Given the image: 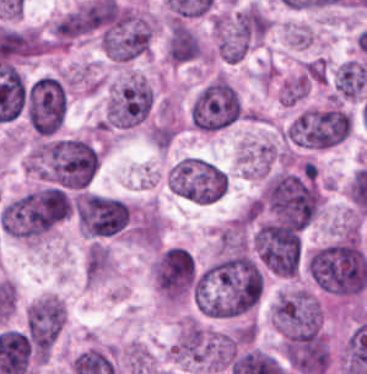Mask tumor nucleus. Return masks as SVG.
<instances>
[{"label": "tumor nucleus", "mask_w": 367, "mask_h": 374, "mask_svg": "<svg viewBox=\"0 0 367 374\" xmlns=\"http://www.w3.org/2000/svg\"><path fill=\"white\" fill-rule=\"evenodd\" d=\"M264 269L250 252L226 248L197 274L192 295L194 305L209 315L244 313L262 294Z\"/></svg>", "instance_id": "1"}, {"label": "tumor nucleus", "mask_w": 367, "mask_h": 374, "mask_svg": "<svg viewBox=\"0 0 367 374\" xmlns=\"http://www.w3.org/2000/svg\"><path fill=\"white\" fill-rule=\"evenodd\" d=\"M99 164V153L86 137L42 136L29 150L26 165L48 183L82 189Z\"/></svg>", "instance_id": "2"}, {"label": "tumor nucleus", "mask_w": 367, "mask_h": 374, "mask_svg": "<svg viewBox=\"0 0 367 374\" xmlns=\"http://www.w3.org/2000/svg\"><path fill=\"white\" fill-rule=\"evenodd\" d=\"M306 270L318 290L338 296L362 292L366 283V253L360 239H334L312 250Z\"/></svg>", "instance_id": "3"}, {"label": "tumor nucleus", "mask_w": 367, "mask_h": 374, "mask_svg": "<svg viewBox=\"0 0 367 374\" xmlns=\"http://www.w3.org/2000/svg\"><path fill=\"white\" fill-rule=\"evenodd\" d=\"M61 217V189L45 185L5 203L0 210V228L11 238L33 242L53 229Z\"/></svg>", "instance_id": "4"}, {"label": "tumor nucleus", "mask_w": 367, "mask_h": 374, "mask_svg": "<svg viewBox=\"0 0 367 374\" xmlns=\"http://www.w3.org/2000/svg\"><path fill=\"white\" fill-rule=\"evenodd\" d=\"M351 114L342 103L306 106L284 125V134L296 146L326 147L349 134Z\"/></svg>", "instance_id": "5"}, {"label": "tumor nucleus", "mask_w": 367, "mask_h": 374, "mask_svg": "<svg viewBox=\"0 0 367 374\" xmlns=\"http://www.w3.org/2000/svg\"><path fill=\"white\" fill-rule=\"evenodd\" d=\"M152 21L146 11L115 4L98 34L103 54L130 60L148 50Z\"/></svg>", "instance_id": "6"}, {"label": "tumor nucleus", "mask_w": 367, "mask_h": 374, "mask_svg": "<svg viewBox=\"0 0 367 374\" xmlns=\"http://www.w3.org/2000/svg\"><path fill=\"white\" fill-rule=\"evenodd\" d=\"M166 180L173 194L200 204L220 199L228 184L220 168L197 156L176 161L166 172Z\"/></svg>", "instance_id": "7"}, {"label": "tumor nucleus", "mask_w": 367, "mask_h": 374, "mask_svg": "<svg viewBox=\"0 0 367 374\" xmlns=\"http://www.w3.org/2000/svg\"><path fill=\"white\" fill-rule=\"evenodd\" d=\"M192 124L215 131L243 114L238 90L223 75H215L201 86L189 106Z\"/></svg>", "instance_id": "8"}, {"label": "tumor nucleus", "mask_w": 367, "mask_h": 374, "mask_svg": "<svg viewBox=\"0 0 367 374\" xmlns=\"http://www.w3.org/2000/svg\"><path fill=\"white\" fill-rule=\"evenodd\" d=\"M152 95L146 77L129 73L111 90L102 112L103 129H127L143 123Z\"/></svg>", "instance_id": "9"}, {"label": "tumor nucleus", "mask_w": 367, "mask_h": 374, "mask_svg": "<svg viewBox=\"0 0 367 374\" xmlns=\"http://www.w3.org/2000/svg\"><path fill=\"white\" fill-rule=\"evenodd\" d=\"M80 229L91 237H112L130 227L134 211L124 200L91 192L75 199Z\"/></svg>", "instance_id": "10"}, {"label": "tumor nucleus", "mask_w": 367, "mask_h": 374, "mask_svg": "<svg viewBox=\"0 0 367 374\" xmlns=\"http://www.w3.org/2000/svg\"><path fill=\"white\" fill-rule=\"evenodd\" d=\"M195 272L193 257L181 244L160 247L152 259V281L160 296L168 301L188 298Z\"/></svg>", "instance_id": "11"}, {"label": "tumor nucleus", "mask_w": 367, "mask_h": 374, "mask_svg": "<svg viewBox=\"0 0 367 374\" xmlns=\"http://www.w3.org/2000/svg\"><path fill=\"white\" fill-rule=\"evenodd\" d=\"M25 111L29 127L36 134H53L66 115V89L52 76L37 77L25 91Z\"/></svg>", "instance_id": "12"}, {"label": "tumor nucleus", "mask_w": 367, "mask_h": 374, "mask_svg": "<svg viewBox=\"0 0 367 374\" xmlns=\"http://www.w3.org/2000/svg\"><path fill=\"white\" fill-rule=\"evenodd\" d=\"M65 320L64 301L43 293L25 310V332L32 353L46 359Z\"/></svg>", "instance_id": "13"}, {"label": "tumor nucleus", "mask_w": 367, "mask_h": 374, "mask_svg": "<svg viewBox=\"0 0 367 374\" xmlns=\"http://www.w3.org/2000/svg\"><path fill=\"white\" fill-rule=\"evenodd\" d=\"M320 316L318 297L306 287L278 292L271 307V320L280 334L314 328L319 324Z\"/></svg>", "instance_id": "14"}, {"label": "tumor nucleus", "mask_w": 367, "mask_h": 374, "mask_svg": "<svg viewBox=\"0 0 367 374\" xmlns=\"http://www.w3.org/2000/svg\"><path fill=\"white\" fill-rule=\"evenodd\" d=\"M201 55V41L186 22L171 20L168 25L166 58L169 64L180 65Z\"/></svg>", "instance_id": "15"}, {"label": "tumor nucleus", "mask_w": 367, "mask_h": 374, "mask_svg": "<svg viewBox=\"0 0 367 374\" xmlns=\"http://www.w3.org/2000/svg\"><path fill=\"white\" fill-rule=\"evenodd\" d=\"M335 97L361 99L367 87V67L362 60L348 59L336 67L332 74Z\"/></svg>", "instance_id": "16"}, {"label": "tumor nucleus", "mask_w": 367, "mask_h": 374, "mask_svg": "<svg viewBox=\"0 0 367 374\" xmlns=\"http://www.w3.org/2000/svg\"><path fill=\"white\" fill-rule=\"evenodd\" d=\"M110 267L109 248L100 241H93L83 263L85 280L97 281Z\"/></svg>", "instance_id": "17"}]
</instances>
